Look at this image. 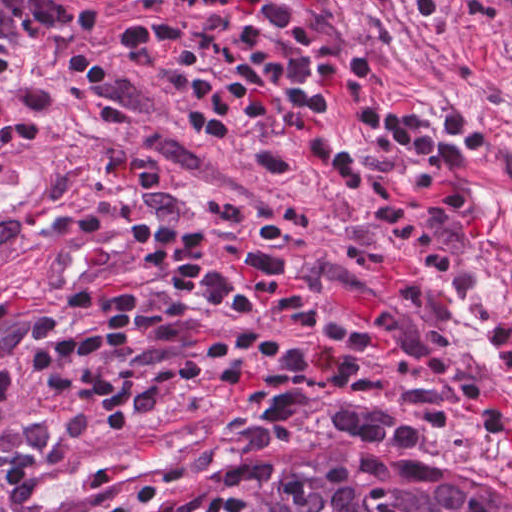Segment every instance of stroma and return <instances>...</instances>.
Returning a JSON list of instances; mask_svg holds the SVG:
<instances>
[{"mask_svg": "<svg viewBox=\"0 0 512 512\" xmlns=\"http://www.w3.org/2000/svg\"><path fill=\"white\" fill-rule=\"evenodd\" d=\"M493 388L509 412L478 402ZM215 395L237 428L114 512L387 455L512 481V43L465 0L50 461Z\"/></svg>", "mask_w": 512, "mask_h": 512, "instance_id": "35a3bbf8", "label": "stroma"}]
</instances>
